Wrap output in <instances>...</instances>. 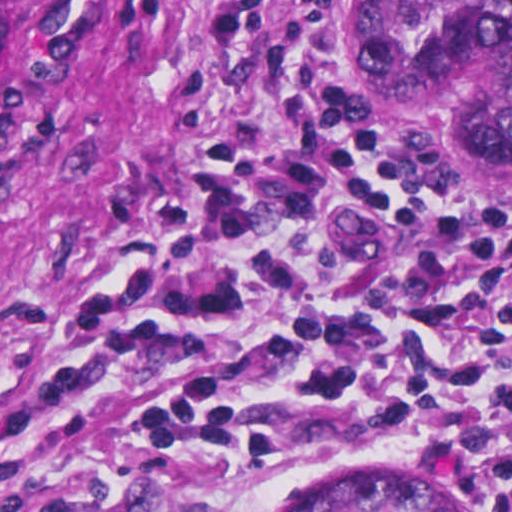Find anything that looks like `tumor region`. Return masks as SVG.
I'll return each instance as SVG.
<instances>
[{"label":"tumor region","mask_w":512,"mask_h":512,"mask_svg":"<svg viewBox=\"0 0 512 512\" xmlns=\"http://www.w3.org/2000/svg\"><path fill=\"white\" fill-rule=\"evenodd\" d=\"M36 0H0V56ZM370 91L434 118L488 193L512 196V0H360ZM301 512H471L400 465L353 468Z\"/></svg>","instance_id":"1"}]
</instances>
